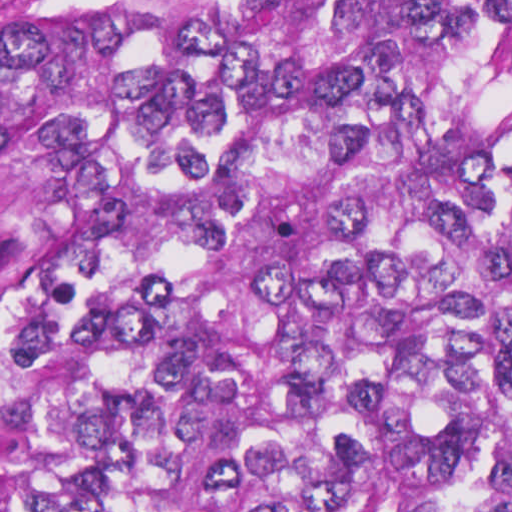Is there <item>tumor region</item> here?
<instances>
[{
	"mask_svg": "<svg viewBox=\"0 0 512 512\" xmlns=\"http://www.w3.org/2000/svg\"><path fill=\"white\" fill-rule=\"evenodd\" d=\"M0 512H512V0H0Z\"/></svg>",
	"mask_w": 512,
	"mask_h": 512,
	"instance_id": "tumor-region-1",
	"label": "tumor region"
}]
</instances>
